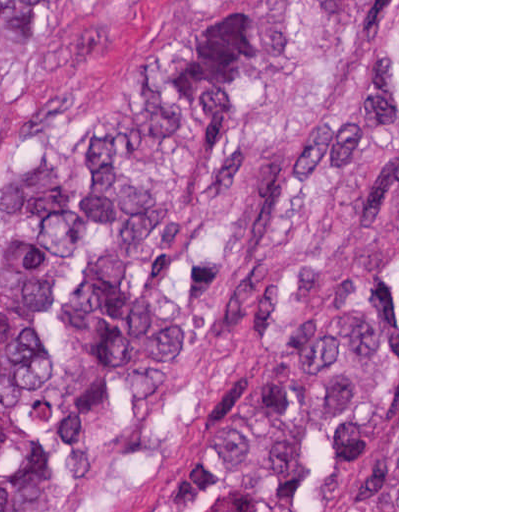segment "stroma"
<instances>
[{
  "mask_svg": "<svg viewBox=\"0 0 512 512\" xmlns=\"http://www.w3.org/2000/svg\"><path fill=\"white\" fill-rule=\"evenodd\" d=\"M249 0L206 7L196 0H146L105 50L93 20L60 23L10 79L0 165L54 118L81 103L130 88L169 48L202 34ZM397 227V512H399V0L397 135L258 266L219 312L211 332L175 372L149 412L102 429L84 491L41 512H142L168 452L202 405L257 348L275 311L328 263L364 249Z\"/></svg>",
  "mask_w": 512,
  "mask_h": 512,
  "instance_id": "obj_1",
  "label": "stroma"
}]
</instances>
